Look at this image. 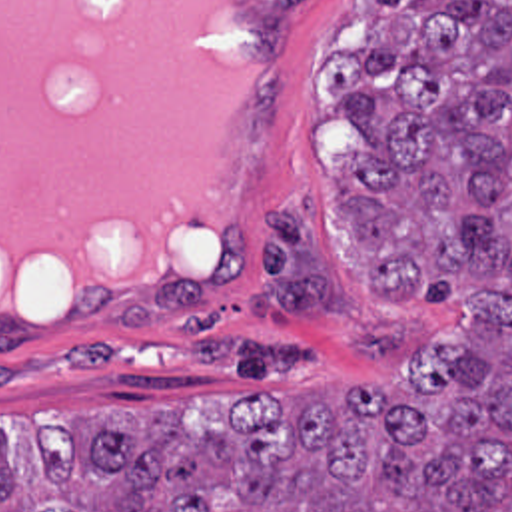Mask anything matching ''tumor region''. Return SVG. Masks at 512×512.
I'll return each instance as SVG.
<instances>
[{"instance_id": "obj_1", "label": "tumor region", "mask_w": 512, "mask_h": 512, "mask_svg": "<svg viewBox=\"0 0 512 512\" xmlns=\"http://www.w3.org/2000/svg\"><path fill=\"white\" fill-rule=\"evenodd\" d=\"M321 86L359 136L333 226L380 304L452 330L394 389L249 393L215 429L53 425L27 475L0 435V512H512V0H370L368 48ZM249 306L345 312L307 200L265 214Z\"/></svg>"}]
</instances>
